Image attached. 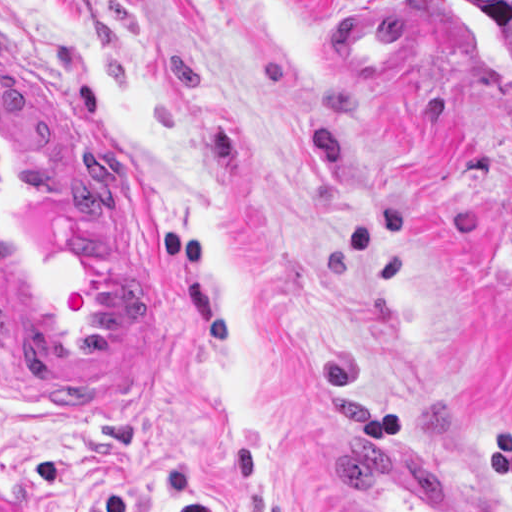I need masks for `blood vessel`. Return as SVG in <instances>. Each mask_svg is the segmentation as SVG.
<instances>
[{
    "instance_id": "obj_1",
    "label": "blood vessel",
    "mask_w": 512,
    "mask_h": 512,
    "mask_svg": "<svg viewBox=\"0 0 512 512\" xmlns=\"http://www.w3.org/2000/svg\"><path fill=\"white\" fill-rule=\"evenodd\" d=\"M0 345L24 394L97 405L175 349V276L134 158L0 56ZM336 441L339 512H494L392 440Z\"/></svg>"
}]
</instances>
